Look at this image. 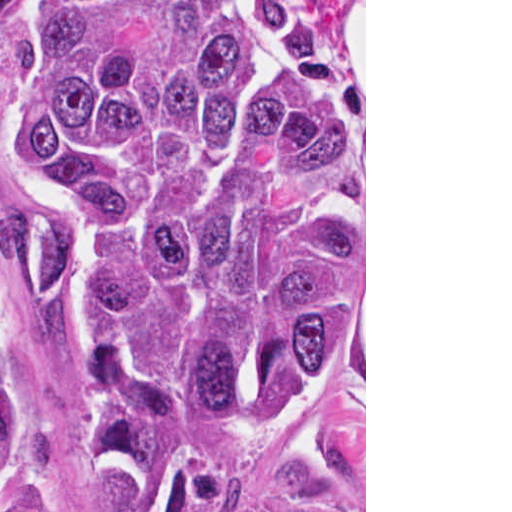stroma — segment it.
<instances>
[{"mask_svg": "<svg viewBox=\"0 0 512 512\" xmlns=\"http://www.w3.org/2000/svg\"><path fill=\"white\" fill-rule=\"evenodd\" d=\"M351 0L330 9L335 22ZM20 43L0 38V222L5 212L46 199L25 178L5 148L1 114L14 52ZM8 326V350L23 394L55 441L87 512L136 511L93 489L81 466L77 443V388L54 332L21 310L0 273ZM271 486H290L330 495L355 512H366V0L364 110V334L333 364L292 436L270 456L258 478L240 495L212 512H242Z\"/></svg>", "mask_w": 512, "mask_h": 512, "instance_id": "stroma-1", "label": "stroma"}]
</instances>
